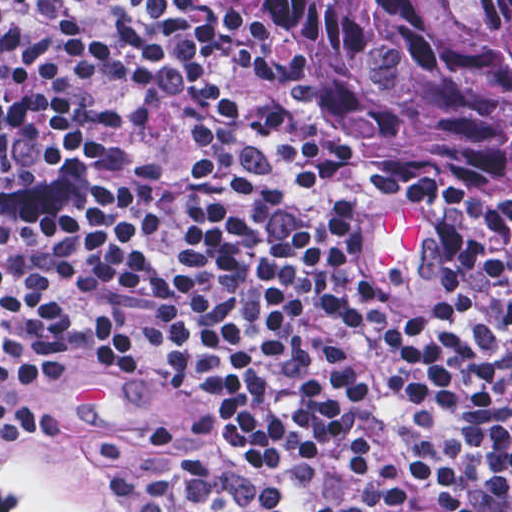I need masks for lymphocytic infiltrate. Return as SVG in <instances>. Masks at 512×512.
Instances as JSON below:
<instances>
[{
    "instance_id": "lymphocytic-infiltrate-1",
    "label": "lymphocytic infiltrate",
    "mask_w": 512,
    "mask_h": 512,
    "mask_svg": "<svg viewBox=\"0 0 512 512\" xmlns=\"http://www.w3.org/2000/svg\"><path fill=\"white\" fill-rule=\"evenodd\" d=\"M385 210L267 0H0V438L119 386L217 423L116 512H512V237Z\"/></svg>"
}]
</instances>
